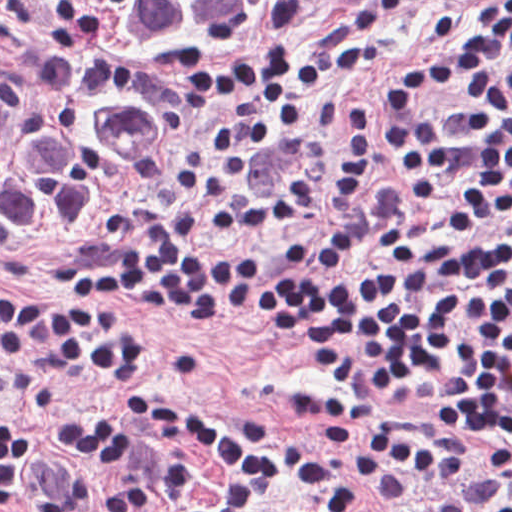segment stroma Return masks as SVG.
I'll use <instances>...</instances> for the list:
<instances>
[{"label":"stroma","mask_w":512,"mask_h":512,"mask_svg":"<svg viewBox=\"0 0 512 512\" xmlns=\"http://www.w3.org/2000/svg\"><path fill=\"white\" fill-rule=\"evenodd\" d=\"M366 1L274 0L215 62L154 161L91 191L74 231L57 248L0 252V287L58 290V283L108 271L128 255L142 221L179 235L170 187L187 145L207 139L216 127L202 94L207 84L232 78L244 62L261 53L313 55L322 37ZM486 1L417 0L392 14L385 23L383 46L367 68L311 92V126L298 144L251 151L249 187L268 193L293 176H303L327 155L348 103H363L373 117L375 146L356 198L344 211L300 219L280 233H251L202 245L279 259L304 276L377 280L512 231L511 210L448 237L433 236L406 191L390 179L380 154V110L393 72L405 60L432 58L443 50L434 35V12H452L469 28ZM129 308L139 314L147 340L159 353L155 371L141 382L145 391L218 417L254 412L287 441L323 445L345 461L347 450L363 438L325 444L312 410L319 397L341 391L370 404V428L390 420L411 436L458 448L465 456L466 477L457 485L401 467L408 488L400 504L376 499L364 476L352 470L363 497V508L356 512H488L493 503L512 500V440L464 431L457 396L441 381L417 378L377 393H359L308 360L292 347L285 330L264 319ZM0 415L23 423L39 437L49 459L71 473L125 476L170 500H203L214 492L215 467L203 457H189L192 485L173 490L137 467L65 446L63 429L78 421L121 423L143 449L161 442L151 426L111 397L90 367L39 362L7 371L0 366ZM271 512L308 511L287 497L275 501Z\"/></svg>","instance_id":"obj_1"}]
</instances>
